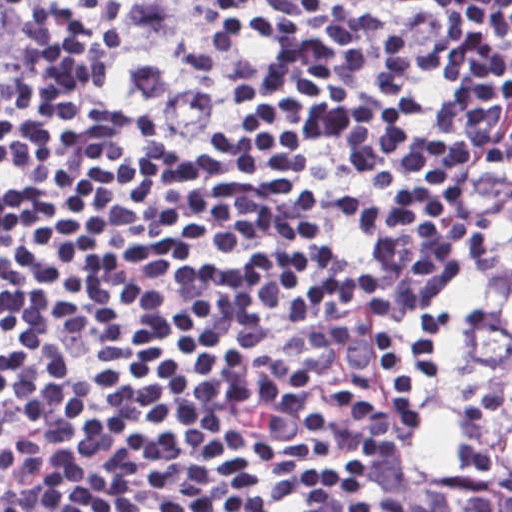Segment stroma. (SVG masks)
I'll use <instances>...</instances> for the list:
<instances>
[{
    "label": "stroma",
    "instance_id": "1",
    "mask_svg": "<svg viewBox=\"0 0 512 512\" xmlns=\"http://www.w3.org/2000/svg\"><path fill=\"white\" fill-rule=\"evenodd\" d=\"M19 2L20 0H0V34L12 18ZM381 23L389 31L396 52H426L446 35L430 28ZM279 38L265 41L248 67ZM54 40L55 37L50 34L33 32L20 44L11 63L0 61V108L12 105L25 97L31 90L41 76L46 54ZM74 75L128 106L165 131L204 150L211 162L214 146L222 131L225 109L238 81L227 93L219 108L202 125H199L183 122L167 115L148 112L128 103L92 81L75 57ZM504 136L505 131L493 149L472 172L451 208L449 252L438 274L417 293L382 313L370 324L389 317L415 314L443 301L458 285L465 271V244L471 213L483 180L497 163L503 149ZM359 327L362 326L323 333L306 342L295 357L299 376L319 418L320 391L329 367L341 347Z\"/></svg>",
    "mask_w": 512,
    "mask_h": 512
}]
</instances>
